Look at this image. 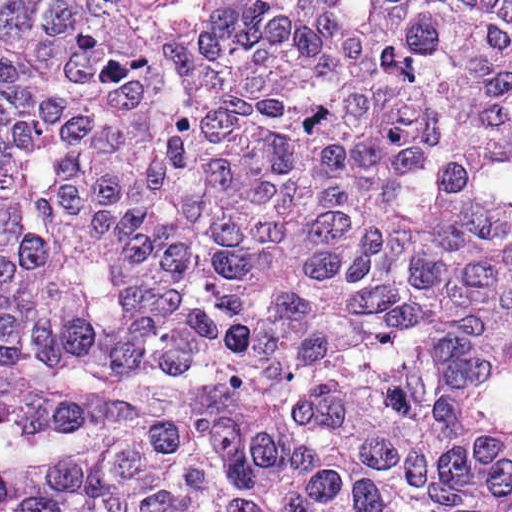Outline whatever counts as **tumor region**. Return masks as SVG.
Masks as SVG:
<instances>
[{
	"label": "tumor region",
	"instance_id": "e687c5a6",
	"mask_svg": "<svg viewBox=\"0 0 512 512\" xmlns=\"http://www.w3.org/2000/svg\"><path fill=\"white\" fill-rule=\"evenodd\" d=\"M0 457L25 512H512V0H0Z\"/></svg>",
	"mask_w": 512,
	"mask_h": 512
}]
</instances>
